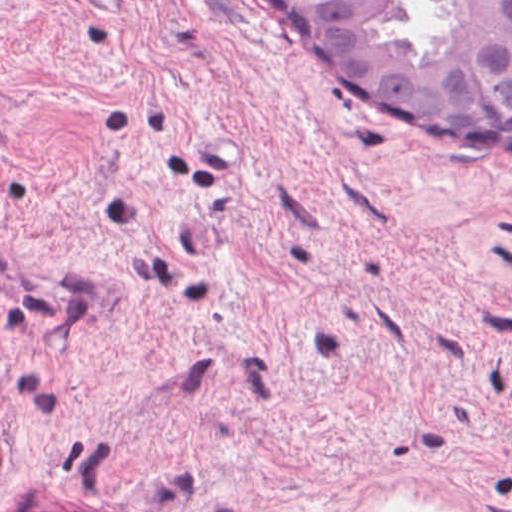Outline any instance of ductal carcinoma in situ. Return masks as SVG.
Instances as JSON below:
<instances>
[{
  "label": "ductal carcinoma in situ",
  "mask_w": 512,
  "mask_h": 512,
  "mask_svg": "<svg viewBox=\"0 0 512 512\" xmlns=\"http://www.w3.org/2000/svg\"><path fill=\"white\" fill-rule=\"evenodd\" d=\"M270 1L348 98L467 153H512V0Z\"/></svg>",
  "instance_id": "0f090b9a"
}]
</instances>
